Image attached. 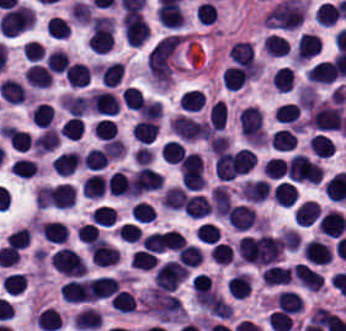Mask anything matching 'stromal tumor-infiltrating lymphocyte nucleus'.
<instances>
[{
  "label": "stromal tumor-infiltrating lymphocyte nucleus",
  "instance_id": "1",
  "mask_svg": "<svg viewBox=\"0 0 346 331\" xmlns=\"http://www.w3.org/2000/svg\"><path fill=\"white\" fill-rule=\"evenodd\" d=\"M342 115V104L318 102L310 111L309 124L326 131L340 129Z\"/></svg>",
  "mask_w": 346,
  "mask_h": 331
},
{
  "label": "stromal tumor-infiltrating lymphocyte nucleus",
  "instance_id": "2",
  "mask_svg": "<svg viewBox=\"0 0 346 331\" xmlns=\"http://www.w3.org/2000/svg\"><path fill=\"white\" fill-rule=\"evenodd\" d=\"M50 262L64 276L81 277L86 274L82 256L73 248L61 247L52 253Z\"/></svg>",
  "mask_w": 346,
  "mask_h": 331
},
{
  "label": "stromal tumor-infiltrating lymphocyte nucleus",
  "instance_id": "3",
  "mask_svg": "<svg viewBox=\"0 0 346 331\" xmlns=\"http://www.w3.org/2000/svg\"><path fill=\"white\" fill-rule=\"evenodd\" d=\"M306 263L326 265L332 259L330 247L322 239H309L302 247Z\"/></svg>",
  "mask_w": 346,
  "mask_h": 331
},
{
  "label": "stromal tumor-infiltrating lymphocyte nucleus",
  "instance_id": "4",
  "mask_svg": "<svg viewBox=\"0 0 346 331\" xmlns=\"http://www.w3.org/2000/svg\"><path fill=\"white\" fill-rule=\"evenodd\" d=\"M291 275L304 289L311 291L323 289V274L303 263H296Z\"/></svg>",
  "mask_w": 346,
  "mask_h": 331
},
{
  "label": "stromal tumor-infiltrating lymphocyte nucleus",
  "instance_id": "5",
  "mask_svg": "<svg viewBox=\"0 0 346 331\" xmlns=\"http://www.w3.org/2000/svg\"><path fill=\"white\" fill-rule=\"evenodd\" d=\"M61 296L69 303L95 301L84 278H70L62 286Z\"/></svg>",
  "mask_w": 346,
  "mask_h": 331
},
{
  "label": "stromal tumor-infiltrating lymphocyte nucleus",
  "instance_id": "6",
  "mask_svg": "<svg viewBox=\"0 0 346 331\" xmlns=\"http://www.w3.org/2000/svg\"><path fill=\"white\" fill-rule=\"evenodd\" d=\"M228 221L236 231H248L257 221L252 207L236 204L227 214Z\"/></svg>",
  "mask_w": 346,
  "mask_h": 331
},
{
  "label": "stromal tumor-infiltrating lymphocyte nucleus",
  "instance_id": "7",
  "mask_svg": "<svg viewBox=\"0 0 346 331\" xmlns=\"http://www.w3.org/2000/svg\"><path fill=\"white\" fill-rule=\"evenodd\" d=\"M319 230L330 238H339L346 228L342 212L327 210L317 224Z\"/></svg>",
  "mask_w": 346,
  "mask_h": 331
},
{
  "label": "stromal tumor-infiltrating lymphocyte nucleus",
  "instance_id": "8",
  "mask_svg": "<svg viewBox=\"0 0 346 331\" xmlns=\"http://www.w3.org/2000/svg\"><path fill=\"white\" fill-rule=\"evenodd\" d=\"M90 297L103 299L110 297L119 288L118 281L113 276L99 275L87 281Z\"/></svg>",
  "mask_w": 346,
  "mask_h": 331
},
{
  "label": "stromal tumor-infiltrating lymphocyte nucleus",
  "instance_id": "9",
  "mask_svg": "<svg viewBox=\"0 0 346 331\" xmlns=\"http://www.w3.org/2000/svg\"><path fill=\"white\" fill-rule=\"evenodd\" d=\"M228 57L233 63L244 68H254L255 57L252 42L238 40L228 49Z\"/></svg>",
  "mask_w": 346,
  "mask_h": 331
},
{
  "label": "stromal tumor-infiltrating lymphocyte nucleus",
  "instance_id": "10",
  "mask_svg": "<svg viewBox=\"0 0 346 331\" xmlns=\"http://www.w3.org/2000/svg\"><path fill=\"white\" fill-rule=\"evenodd\" d=\"M0 130L11 149L16 152L27 151L31 144V137L27 131L9 125H1Z\"/></svg>",
  "mask_w": 346,
  "mask_h": 331
},
{
  "label": "stromal tumor-infiltrating lymphocyte nucleus",
  "instance_id": "11",
  "mask_svg": "<svg viewBox=\"0 0 346 331\" xmlns=\"http://www.w3.org/2000/svg\"><path fill=\"white\" fill-rule=\"evenodd\" d=\"M40 234L51 244H64L68 239V228L62 221H42Z\"/></svg>",
  "mask_w": 346,
  "mask_h": 331
},
{
  "label": "stromal tumor-infiltrating lymphocyte nucleus",
  "instance_id": "12",
  "mask_svg": "<svg viewBox=\"0 0 346 331\" xmlns=\"http://www.w3.org/2000/svg\"><path fill=\"white\" fill-rule=\"evenodd\" d=\"M322 42L318 35L310 32H302L296 42L295 57L305 61L316 53Z\"/></svg>",
  "mask_w": 346,
  "mask_h": 331
},
{
  "label": "stromal tumor-infiltrating lymphocyte nucleus",
  "instance_id": "13",
  "mask_svg": "<svg viewBox=\"0 0 346 331\" xmlns=\"http://www.w3.org/2000/svg\"><path fill=\"white\" fill-rule=\"evenodd\" d=\"M270 186L265 179L244 181L241 193L243 200L261 202L269 196Z\"/></svg>",
  "mask_w": 346,
  "mask_h": 331
},
{
  "label": "stromal tumor-infiltrating lymphocyte nucleus",
  "instance_id": "14",
  "mask_svg": "<svg viewBox=\"0 0 346 331\" xmlns=\"http://www.w3.org/2000/svg\"><path fill=\"white\" fill-rule=\"evenodd\" d=\"M336 68L332 61H318L306 72L312 84H332Z\"/></svg>",
  "mask_w": 346,
  "mask_h": 331
},
{
  "label": "stromal tumor-infiltrating lymphocyte nucleus",
  "instance_id": "15",
  "mask_svg": "<svg viewBox=\"0 0 346 331\" xmlns=\"http://www.w3.org/2000/svg\"><path fill=\"white\" fill-rule=\"evenodd\" d=\"M103 86H116L124 73V66L120 61L99 63L96 67Z\"/></svg>",
  "mask_w": 346,
  "mask_h": 331
},
{
  "label": "stromal tumor-infiltrating lymphocyte nucleus",
  "instance_id": "16",
  "mask_svg": "<svg viewBox=\"0 0 346 331\" xmlns=\"http://www.w3.org/2000/svg\"><path fill=\"white\" fill-rule=\"evenodd\" d=\"M63 74L68 84L77 89L90 83L91 73L85 63L72 62Z\"/></svg>",
  "mask_w": 346,
  "mask_h": 331
},
{
  "label": "stromal tumor-infiltrating lymphocyte nucleus",
  "instance_id": "17",
  "mask_svg": "<svg viewBox=\"0 0 346 331\" xmlns=\"http://www.w3.org/2000/svg\"><path fill=\"white\" fill-rule=\"evenodd\" d=\"M101 313L94 307L84 306L74 315L72 326L81 330L100 327Z\"/></svg>",
  "mask_w": 346,
  "mask_h": 331
},
{
  "label": "stromal tumor-infiltrating lymphocyte nucleus",
  "instance_id": "18",
  "mask_svg": "<svg viewBox=\"0 0 346 331\" xmlns=\"http://www.w3.org/2000/svg\"><path fill=\"white\" fill-rule=\"evenodd\" d=\"M275 303L280 311L289 314H297L303 307L301 295L294 290H280Z\"/></svg>",
  "mask_w": 346,
  "mask_h": 331
},
{
  "label": "stromal tumor-infiltrating lymphocyte nucleus",
  "instance_id": "19",
  "mask_svg": "<svg viewBox=\"0 0 346 331\" xmlns=\"http://www.w3.org/2000/svg\"><path fill=\"white\" fill-rule=\"evenodd\" d=\"M321 215L317 201L305 200L294 211V222L300 226H308Z\"/></svg>",
  "mask_w": 346,
  "mask_h": 331
},
{
  "label": "stromal tumor-infiltrating lymphocyte nucleus",
  "instance_id": "20",
  "mask_svg": "<svg viewBox=\"0 0 346 331\" xmlns=\"http://www.w3.org/2000/svg\"><path fill=\"white\" fill-rule=\"evenodd\" d=\"M222 79L227 90L236 91L250 79V72L237 65H230L222 72Z\"/></svg>",
  "mask_w": 346,
  "mask_h": 331
},
{
  "label": "stromal tumor-infiltrating lymphocyte nucleus",
  "instance_id": "21",
  "mask_svg": "<svg viewBox=\"0 0 346 331\" xmlns=\"http://www.w3.org/2000/svg\"><path fill=\"white\" fill-rule=\"evenodd\" d=\"M262 48L270 57H278L290 52L289 41L276 32H269L267 34Z\"/></svg>",
  "mask_w": 346,
  "mask_h": 331
},
{
  "label": "stromal tumor-infiltrating lymphocyte nucleus",
  "instance_id": "22",
  "mask_svg": "<svg viewBox=\"0 0 346 331\" xmlns=\"http://www.w3.org/2000/svg\"><path fill=\"white\" fill-rule=\"evenodd\" d=\"M25 81L36 87H48L51 83V75L48 70L39 63L29 65L24 74Z\"/></svg>",
  "mask_w": 346,
  "mask_h": 331
},
{
  "label": "stromal tumor-infiltrating lymphocyte nucleus",
  "instance_id": "23",
  "mask_svg": "<svg viewBox=\"0 0 346 331\" xmlns=\"http://www.w3.org/2000/svg\"><path fill=\"white\" fill-rule=\"evenodd\" d=\"M158 130V122L140 119L135 122L131 129L133 137L142 143H150Z\"/></svg>",
  "mask_w": 346,
  "mask_h": 331
},
{
  "label": "stromal tumor-infiltrating lymphocyte nucleus",
  "instance_id": "24",
  "mask_svg": "<svg viewBox=\"0 0 346 331\" xmlns=\"http://www.w3.org/2000/svg\"><path fill=\"white\" fill-rule=\"evenodd\" d=\"M187 191L179 185H172L165 190L161 205L165 210H180L185 202Z\"/></svg>",
  "mask_w": 346,
  "mask_h": 331
},
{
  "label": "stromal tumor-infiltrating lymphocyte nucleus",
  "instance_id": "25",
  "mask_svg": "<svg viewBox=\"0 0 346 331\" xmlns=\"http://www.w3.org/2000/svg\"><path fill=\"white\" fill-rule=\"evenodd\" d=\"M79 156L74 151H67L58 154L51 160V165L55 172L60 175L70 174L78 165Z\"/></svg>",
  "mask_w": 346,
  "mask_h": 331
},
{
  "label": "stromal tumor-infiltrating lymphocyte nucleus",
  "instance_id": "26",
  "mask_svg": "<svg viewBox=\"0 0 346 331\" xmlns=\"http://www.w3.org/2000/svg\"><path fill=\"white\" fill-rule=\"evenodd\" d=\"M210 210V205L208 203L207 197L201 194L189 195L183 212L186 216H191L195 218L205 217L207 212Z\"/></svg>",
  "mask_w": 346,
  "mask_h": 331
},
{
  "label": "stromal tumor-infiltrating lymphocyte nucleus",
  "instance_id": "27",
  "mask_svg": "<svg viewBox=\"0 0 346 331\" xmlns=\"http://www.w3.org/2000/svg\"><path fill=\"white\" fill-rule=\"evenodd\" d=\"M250 278L244 272H237L226 281V289L235 298H244L249 295Z\"/></svg>",
  "mask_w": 346,
  "mask_h": 331
},
{
  "label": "stromal tumor-infiltrating lymphocyte nucleus",
  "instance_id": "28",
  "mask_svg": "<svg viewBox=\"0 0 346 331\" xmlns=\"http://www.w3.org/2000/svg\"><path fill=\"white\" fill-rule=\"evenodd\" d=\"M265 285H279L290 281V268L270 264L262 270Z\"/></svg>",
  "mask_w": 346,
  "mask_h": 331
},
{
  "label": "stromal tumor-infiltrating lymphocyte nucleus",
  "instance_id": "29",
  "mask_svg": "<svg viewBox=\"0 0 346 331\" xmlns=\"http://www.w3.org/2000/svg\"><path fill=\"white\" fill-rule=\"evenodd\" d=\"M33 319L40 331H55L60 322L58 311L48 306L40 309Z\"/></svg>",
  "mask_w": 346,
  "mask_h": 331
},
{
  "label": "stromal tumor-infiltrating lymphocyte nucleus",
  "instance_id": "30",
  "mask_svg": "<svg viewBox=\"0 0 346 331\" xmlns=\"http://www.w3.org/2000/svg\"><path fill=\"white\" fill-rule=\"evenodd\" d=\"M273 115L279 121L300 126V105L296 102H283L275 107Z\"/></svg>",
  "mask_w": 346,
  "mask_h": 331
},
{
  "label": "stromal tumor-infiltrating lymphocyte nucleus",
  "instance_id": "31",
  "mask_svg": "<svg viewBox=\"0 0 346 331\" xmlns=\"http://www.w3.org/2000/svg\"><path fill=\"white\" fill-rule=\"evenodd\" d=\"M109 302L112 310L119 313H132L136 304L132 292L121 289L114 293Z\"/></svg>",
  "mask_w": 346,
  "mask_h": 331
},
{
  "label": "stromal tumor-infiltrating lymphocyte nucleus",
  "instance_id": "32",
  "mask_svg": "<svg viewBox=\"0 0 346 331\" xmlns=\"http://www.w3.org/2000/svg\"><path fill=\"white\" fill-rule=\"evenodd\" d=\"M273 148L279 150H289L297 141L291 128L279 127L272 132L269 138Z\"/></svg>",
  "mask_w": 346,
  "mask_h": 331
},
{
  "label": "stromal tumor-infiltrating lymphocyte nucleus",
  "instance_id": "33",
  "mask_svg": "<svg viewBox=\"0 0 346 331\" xmlns=\"http://www.w3.org/2000/svg\"><path fill=\"white\" fill-rule=\"evenodd\" d=\"M82 185L88 198H101L105 195V175L93 173L83 179Z\"/></svg>",
  "mask_w": 346,
  "mask_h": 331
},
{
  "label": "stromal tumor-infiltrating lymphocyte nucleus",
  "instance_id": "34",
  "mask_svg": "<svg viewBox=\"0 0 346 331\" xmlns=\"http://www.w3.org/2000/svg\"><path fill=\"white\" fill-rule=\"evenodd\" d=\"M54 202L58 210H65L73 206L75 199L74 186L70 184H57L53 188Z\"/></svg>",
  "mask_w": 346,
  "mask_h": 331
},
{
  "label": "stromal tumor-infiltrating lymphocyte nucleus",
  "instance_id": "35",
  "mask_svg": "<svg viewBox=\"0 0 346 331\" xmlns=\"http://www.w3.org/2000/svg\"><path fill=\"white\" fill-rule=\"evenodd\" d=\"M297 200V189L290 181H282L275 186L274 202L281 206H291Z\"/></svg>",
  "mask_w": 346,
  "mask_h": 331
},
{
  "label": "stromal tumor-infiltrating lymphocyte nucleus",
  "instance_id": "36",
  "mask_svg": "<svg viewBox=\"0 0 346 331\" xmlns=\"http://www.w3.org/2000/svg\"><path fill=\"white\" fill-rule=\"evenodd\" d=\"M206 97L202 89L190 88L179 100V105L186 111H197L205 105Z\"/></svg>",
  "mask_w": 346,
  "mask_h": 331
},
{
  "label": "stromal tumor-infiltrating lymphocyte nucleus",
  "instance_id": "37",
  "mask_svg": "<svg viewBox=\"0 0 346 331\" xmlns=\"http://www.w3.org/2000/svg\"><path fill=\"white\" fill-rule=\"evenodd\" d=\"M107 194L126 195L128 192V180L121 170H114L105 181Z\"/></svg>",
  "mask_w": 346,
  "mask_h": 331
},
{
  "label": "stromal tumor-infiltrating lymphocyte nucleus",
  "instance_id": "38",
  "mask_svg": "<svg viewBox=\"0 0 346 331\" xmlns=\"http://www.w3.org/2000/svg\"><path fill=\"white\" fill-rule=\"evenodd\" d=\"M109 156L104 149L99 147H91L83 156L82 163L93 170L102 169L109 161Z\"/></svg>",
  "mask_w": 346,
  "mask_h": 331
},
{
  "label": "stromal tumor-infiltrating lymphocyte nucleus",
  "instance_id": "39",
  "mask_svg": "<svg viewBox=\"0 0 346 331\" xmlns=\"http://www.w3.org/2000/svg\"><path fill=\"white\" fill-rule=\"evenodd\" d=\"M335 144V142L323 133H316L310 138L309 148L312 153L324 158L332 153Z\"/></svg>",
  "mask_w": 346,
  "mask_h": 331
},
{
  "label": "stromal tumor-infiltrating lymphocyte nucleus",
  "instance_id": "40",
  "mask_svg": "<svg viewBox=\"0 0 346 331\" xmlns=\"http://www.w3.org/2000/svg\"><path fill=\"white\" fill-rule=\"evenodd\" d=\"M295 74L292 68L280 67L275 70L272 82L279 92H287L294 86Z\"/></svg>",
  "mask_w": 346,
  "mask_h": 331
},
{
  "label": "stromal tumor-infiltrating lymphocyte nucleus",
  "instance_id": "41",
  "mask_svg": "<svg viewBox=\"0 0 346 331\" xmlns=\"http://www.w3.org/2000/svg\"><path fill=\"white\" fill-rule=\"evenodd\" d=\"M157 260L158 257L154 252L141 248L131 254L130 266L140 270H152Z\"/></svg>",
  "mask_w": 346,
  "mask_h": 331
},
{
  "label": "stromal tumor-infiltrating lymphocyte nucleus",
  "instance_id": "42",
  "mask_svg": "<svg viewBox=\"0 0 346 331\" xmlns=\"http://www.w3.org/2000/svg\"><path fill=\"white\" fill-rule=\"evenodd\" d=\"M69 62L70 60L67 52L60 49H53L45 57V63L48 70H51L54 73H64Z\"/></svg>",
  "mask_w": 346,
  "mask_h": 331
},
{
  "label": "stromal tumor-infiltrating lymphocyte nucleus",
  "instance_id": "43",
  "mask_svg": "<svg viewBox=\"0 0 346 331\" xmlns=\"http://www.w3.org/2000/svg\"><path fill=\"white\" fill-rule=\"evenodd\" d=\"M177 259L194 268L202 261V252L191 243H184L178 248Z\"/></svg>",
  "mask_w": 346,
  "mask_h": 331
},
{
  "label": "stromal tumor-infiltrating lymphocyte nucleus",
  "instance_id": "44",
  "mask_svg": "<svg viewBox=\"0 0 346 331\" xmlns=\"http://www.w3.org/2000/svg\"><path fill=\"white\" fill-rule=\"evenodd\" d=\"M54 118V110L47 102H40L32 107L31 120L40 127H47Z\"/></svg>",
  "mask_w": 346,
  "mask_h": 331
},
{
  "label": "stromal tumor-infiltrating lymphocyte nucleus",
  "instance_id": "45",
  "mask_svg": "<svg viewBox=\"0 0 346 331\" xmlns=\"http://www.w3.org/2000/svg\"><path fill=\"white\" fill-rule=\"evenodd\" d=\"M90 221L94 224L109 226L116 221V215L113 207L99 205L94 207L89 214Z\"/></svg>",
  "mask_w": 346,
  "mask_h": 331
},
{
  "label": "stromal tumor-infiltrating lymphocyte nucleus",
  "instance_id": "46",
  "mask_svg": "<svg viewBox=\"0 0 346 331\" xmlns=\"http://www.w3.org/2000/svg\"><path fill=\"white\" fill-rule=\"evenodd\" d=\"M233 257V248L228 242H215L211 247L210 259L216 264H229Z\"/></svg>",
  "mask_w": 346,
  "mask_h": 331
},
{
  "label": "stromal tumor-infiltrating lymphocyte nucleus",
  "instance_id": "47",
  "mask_svg": "<svg viewBox=\"0 0 346 331\" xmlns=\"http://www.w3.org/2000/svg\"><path fill=\"white\" fill-rule=\"evenodd\" d=\"M185 148L175 139H168L163 146V160L169 164H178L184 157Z\"/></svg>",
  "mask_w": 346,
  "mask_h": 331
},
{
  "label": "stromal tumor-infiltrating lymphocyte nucleus",
  "instance_id": "48",
  "mask_svg": "<svg viewBox=\"0 0 346 331\" xmlns=\"http://www.w3.org/2000/svg\"><path fill=\"white\" fill-rule=\"evenodd\" d=\"M315 14L318 22L329 26L338 19L337 4L327 0L323 1Z\"/></svg>",
  "mask_w": 346,
  "mask_h": 331
},
{
  "label": "stromal tumor-infiltrating lymphocyte nucleus",
  "instance_id": "49",
  "mask_svg": "<svg viewBox=\"0 0 346 331\" xmlns=\"http://www.w3.org/2000/svg\"><path fill=\"white\" fill-rule=\"evenodd\" d=\"M140 118L159 119L163 113V107L157 99H143L137 107Z\"/></svg>",
  "mask_w": 346,
  "mask_h": 331
},
{
  "label": "stromal tumor-infiltrating lymphocyte nucleus",
  "instance_id": "50",
  "mask_svg": "<svg viewBox=\"0 0 346 331\" xmlns=\"http://www.w3.org/2000/svg\"><path fill=\"white\" fill-rule=\"evenodd\" d=\"M67 138H80L84 132V121L78 116H70L58 131Z\"/></svg>",
  "mask_w": 346,
  "mask_h": 331
},
{
  "label": "stromal tumor-infiltrating lymphocyte nucleus",
  "instance_id": "51",
  "mask_svg": "<svg viewBox=\"0 0 346 331\" xmlns=\"http://www.w3.org/2000/svg\"><path fill=\"white\" fill-rule=\"evenodd\" d=\"M91 132L98 139L111 140L117 130L111 119L108 117H101L93 123Z\"/></svg>",
  "mask_w": 346,
  "mask_h": 331
},
{
  "label": "stromal tumor-infiltrating lymphocyte nucleus",
  "instance_id": "52",
  "mask_svg": "<svg viewBox=\"0 0 346 331\" xmlns=\"http://www.w3.org/2000/svg\"><path fill=\"white\" fill-rule=\"evenodd\" d=\"M227 107L223 100H216L210 108V124L215 131H222Z\"/></svg>",
  "mask_w": 346,
  "mask_h": 331
},
{
  "label": "stromal tumor-infiltrating lymphocyte nucleus",
  "instance_id": "53",
  "mask_svg": "<svg viewBox=\"0 0 346 331\" xmlns=\"http://www.w3.org/2000/svg\"><path fill=\"white\" fill-rule=\"evenodd\" d=\"M54 193L49 186L38 185L33 195V205L40 209H45L54 203Z\"/></svg>",
  "mask_w": 346,
  "mask_h": 331
},
{
  "label": "stromal tumor-infiltrating lymphocyte nucleus",
  "instance_id": "54",
  "mask_svg": "<svg viewBox=\"0 0 346 331\" xmlns=\"http://www.w3.org/2000/svg\"><path fill=\"white\" fill-rule=\"evenodd\" d=\"M155 218V209L152 204L145 201H137L133 206L132 219L142 223L153 222Z\"/></svg>",
  "mask_w": 346,
  "mask_h": 331
},
{
  "label": "stromal tumor-infiltrating lymphocyte nucleus",
  "instance_id": "55",
  "mask_svg": "<svg viewBox=\"0 0 346 331\" xmlns=\"http://www.w3.org/2000/svg\"><path fill=\"white\" fill-rule=\"evenodd\" d=\"M262 170L268 179H280L285 175V162L281 158L269 157Z\"/></svg>",
  "mask_w": 346,
  "mask_h": 331
},
{
  "label": "stromal tumor-infiltrating lymphocyte nucleus",
  "instance_id": "56",
  "mask_svg": "<svg viewBox=\"0 0 346 331\" xmlns=\"http://www.w3.org/2000/svg\"><path fill=\"white\" fill-rule=\"evenodd\" d=\"M47 33L54 37L65 38L69 35V25L67 21L59 16H52L48 19L46 25Z\"/></svg>",
  "mask_w": 346,
  "mask_h": 331
},
{
  "label": "stromal tumor-infiltrating lymphocyte nucleus",
  "instance_id": "57",
  "mask_svg": "<svg viewBox=\"0 0 346 331\" xmlns=\"http://www.w3.org/2000/svg\"><path fill=\"white\" fill-rule=\"evenodd\" d=\"M217 7L211 0H204L195 14L201 24H211L216 18Z\"/></svg>",
  "mask_w": 346,
  "mask_h": 331
},
{
  "label": "stromal tumor-infiltrating lymphocyte nucleus",
  "instance_id": "58",
  "mask_svg": "<svg viewBox=\"0 0 346 331\" xmlns=\"http://www.w3.org/2000/svg\"><path fill=\"white\" fill-rule=\"evenodd\" d=\"M194 233L199 239L200 243L211 245L218 240L220 234L217 227L206 222L200 225Z\"/></svg>",
  "mask_w": 346,
  "mask_h": 331
},
{
  "label": "stromal tumor-infiltrating lymphocyte nucleus",
  "instance_id": "59",
  "mask_svg": "<svg viewBox=\"0 0 346 331\" xmlns=\"http://www.w3.org/2000/svg\"><path fill=\"white\" fill-rule=\"evenodd\" d=\"M121 97L126 106L135 111L144 99L138 88L129 85L123 90Z\"/></svg>",
  "mask_w": 346,
  "mask_h": 331
},
{
  "label": "stromal tumor-infiltrating lymphocyte nucleus",
  "instance_id": "60",
  "mask_svg": "<svg viewBox=\"0 0 346 331\" xmlns=\"http://www.w3.org/2000/svg\"><path fill=\"white\" fill-rule=\"evenodd\" d=\"M140 232V229L134 223H121L115 231L120 240L131 243L138 238Z\"/></svg>",
  "mask_w": 346,
  "mask_h": 331
},
{
  "label": "stromal tumor-infiltrating lymphocyte nucleus",
  "instance_id": "61",
  "mask_svg": "<svg viewBox=\"0 0 346 331\" xmlns=\"http://www.w3.org/2000/svg\"><path fill=\"white\" fill-rule=\"evenodd\" d=\"M208 145L214 154H218L227 149L229 144V137L221 133H214L211 137L207 139Z\"/></svg>",
  "mask_w": 346,
  "mask_h": 331
}]
</instances>
